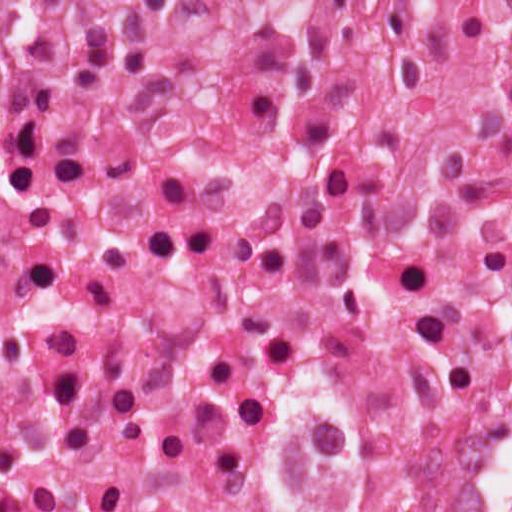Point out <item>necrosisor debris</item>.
<instances>
[{
  "label": "necrosis or debris",
  "instance_id": "necrosis-or-debris-1",
  "mask_svg": "<svg viewBox=\"0 0 512 512\" xmlns=\"http://www.w3.org/2000/svg\"><path fill=\"white\" fill-rule=\"evenodd\" d=\"M0 512H512V0H9Z\"/></svg>",
  "mask_w": 512,
  "mask_h": 512
}]
</instances>
